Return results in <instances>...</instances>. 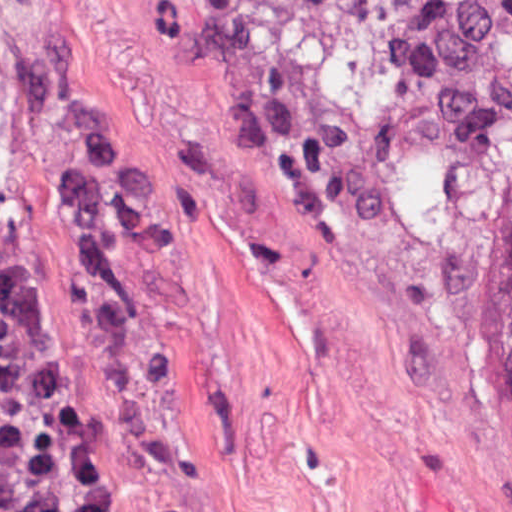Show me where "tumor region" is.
<instances>
[{
	"label": "tumor region",
	"mask_w": 512,
	"mask_h": 512,
	"mask_svg": "<svg viewBox=\"0 0 512 512\" xmlns=\"http://www.w3.org/2000/svg\"><path fill=\"white\" fill-rule=\"evenodd\" d=\"M269 67L452 253L512 384V0H241ZM0 512H99L0 201Z\"/></svg>",
	"instance_id": "tumor-region-1"
}]
</instances>
